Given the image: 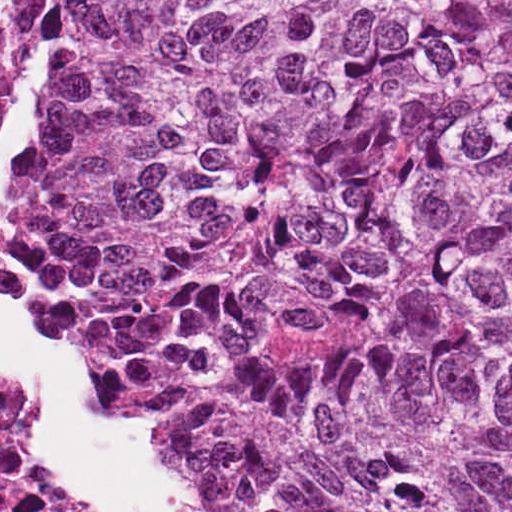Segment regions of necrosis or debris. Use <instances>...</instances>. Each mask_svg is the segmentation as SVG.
Here are the masks:
<instances>
[{"instance_id": "1", "label": "necrosis or debris", "mask_w": 512, "mask_h": 512, "mask_svg": "<svg viewBox=\"0 0 512 512\" xmlns=\"http://www.w3.org/2000/svg\"><path fill=\"white\" fill-rule=\"evenodd\" d=\"M0 512H97L94 486L39 468L31 387H0Z\"/></svg>"}]
</instances>
